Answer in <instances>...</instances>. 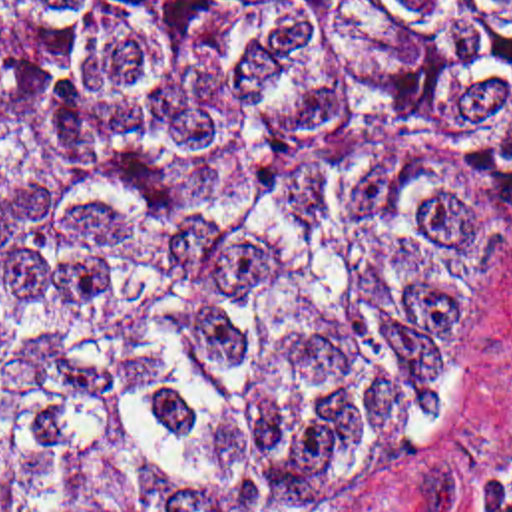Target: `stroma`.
I'll list each match as a JSON object with an SVG mask.
<instances>
[{
    "label": "stroma",
    "instance_id": "1",
    "mask_svg": "<svg viewBox=\"0 0 512 512\" xmlns=\"http://www.w3.org/2000/svg\"><path fill=\"white\" fill-rule=\"evenodd\" d=\"M512 460V227L491 265L473 336L429 428L368 512H475Z\"/></svg>",
    "mask_w": 512,
    "mask_h": 512
}]
</instances>
